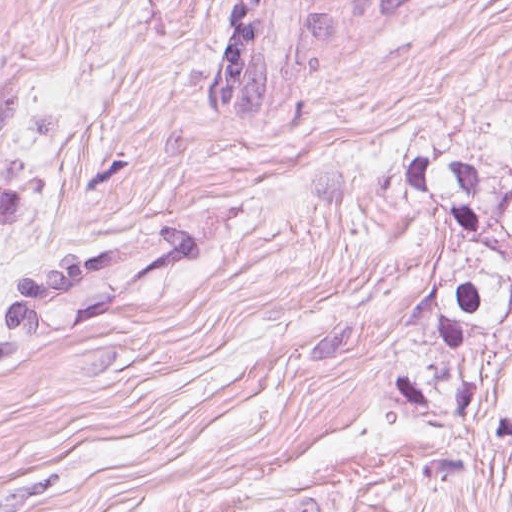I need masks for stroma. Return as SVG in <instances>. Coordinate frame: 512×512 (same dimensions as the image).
<instances>
[{
  "mask_svg": "<svg viewBox=\"0 0 512 512\" xmlns=\"http://www.w3.org/2000/svg\"><path fill=\"white\" fill-rule=\"evenodd\" d=\"M230 1L0 0V300L18 268L248 220L0 360V512H512V448L386 394L441 277L386 181L429 150L512 165V0L423 8L220 121Z\"/></svg>",
  "mask_w": 512,
  "mask_h": 512,
  "instance_id": "stroma-1",
  "label": "stroma"
}]
</instances>
